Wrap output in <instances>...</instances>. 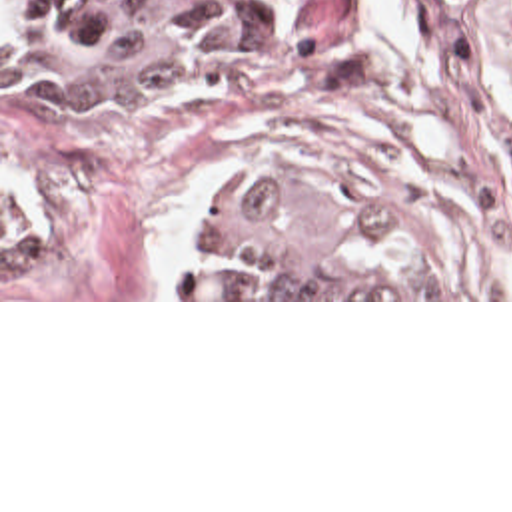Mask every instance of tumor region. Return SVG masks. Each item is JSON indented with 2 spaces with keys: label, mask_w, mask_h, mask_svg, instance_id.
Listing matches in <instances>:
<instances>
[{
  "label": "tumor region",
  "mask_w": 512,
  "mask_h": 512,
  "mask_svg": "<svg viewBox=\"0 0 512 512\" xmlns=\"http://www.w3.org/2000/svg\"><path fill=\"white\" fill-rule=\"evenodd\" d=\"M260 42L238 0H2V102L164 92ZM313 178L238 180L196 298H421L397 228Z\"/></svg>",
  "instance_id": "1"
}]
</instances>
